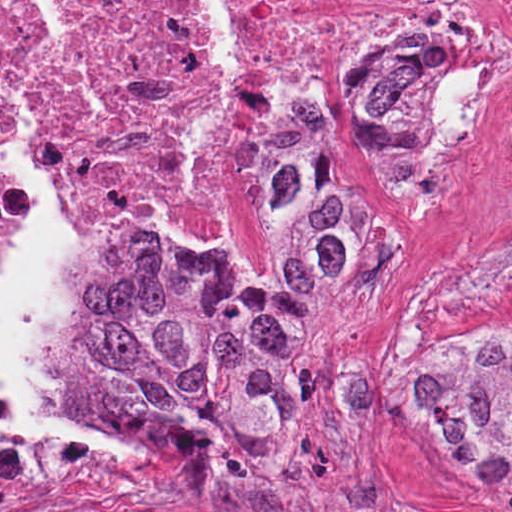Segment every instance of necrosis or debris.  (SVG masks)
<instances>
[{"instance_id": "necrosis-or-debris-1", "label": "necrosis or debris", "mask_w": 512, "mask_h": 512, "mask_svg": "<svg viewBox=\"0 0 512 512\" xmlns=\"http://www.w3.org/2000/svg\"><path fill=\"white\" fill-rule=\"evenodd\" d=\"M61 22L46 0H0V75L43 178L105 219L116 245L151 236L212 273L263 280L276 271L258 208V143L268 112L322 121L335 106L325 36L356 74L373 50L430 45L436 68L412 124L431 178H454L512 128V0H237L238 59L218 112V70L177 0H71ZM359 202L351 283L383 260L373 203L351 155ZM20 175L0 163V254L26 223ZM107 261L89 295L103 283ZM133 433L189 459L165 433ZM276 433H269L266 436ZM125 461L64 433L0 427V488L106 478Z\"/></svg>"}]
</instances>
